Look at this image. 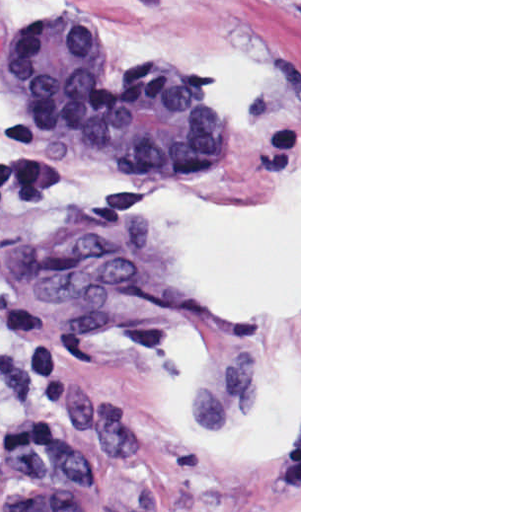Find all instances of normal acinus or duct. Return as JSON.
I'll use <instances>...</instances> for the list:
<instances>
[{
	"instance_id": "obj_1",
	"label": "normal acinus or duct",
	"mask_w": 512,
	"mask_h": 512,
	"mask_svg": "<svg viewBox=\"0 0 512 512\" xmlns=\"http://www.w3.org/2000/svg\"><path fill=\"white\" fill-rule=\"evenodd\" d=\"M57 22L0 49L6 81L73 151L133 176L181 179L227 140L212 73L181 61H129L113 73ZM10 512H97L86 450L59 434L34 438Z\"/></svg>"
}]
</instances>
